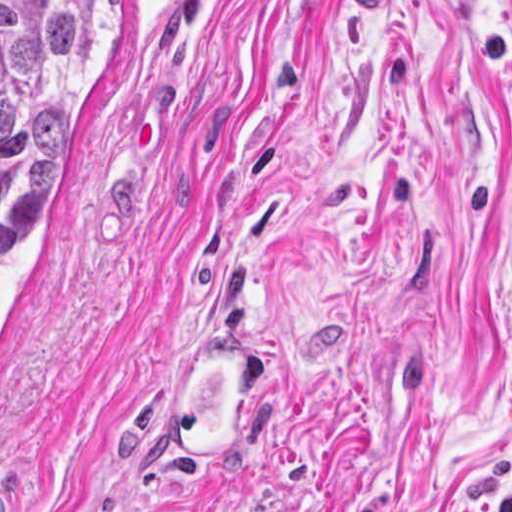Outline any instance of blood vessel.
<instances>
[{"mask_svg": "<svg viewBox=\"0 0 512 512\" xmlns=\"http://www.w3.org/2000/svg\"><path fill=\"white\" fill-rule=\"evenodd\" d=\"M163 392L158 429L169 456L187 470H207L236 436L247 412L255 375V343L212 335ZM14 495L0 485V512Z\"/></svg>", "mask_w": 512, "mask_h": 512, "instance_id": "blood-vessel-1", "label": "blood vessel"}]
</instances>
